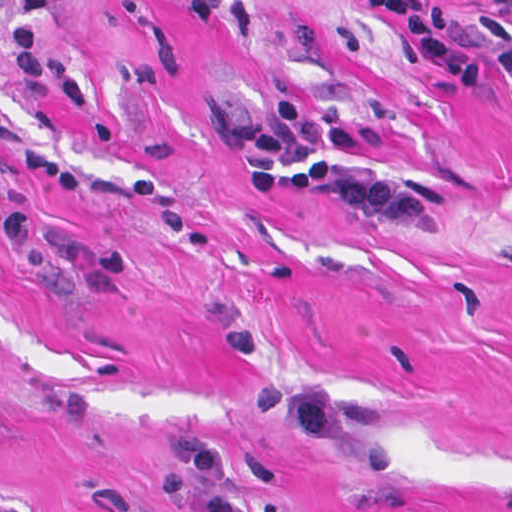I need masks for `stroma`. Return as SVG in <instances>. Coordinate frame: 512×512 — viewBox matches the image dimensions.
<instances>
[{"instance_id": "35a3bbf8", "label": "stroma", "mask_w": 512, "mask_h": 512, "mask_svg": "<svg viewBox=\"0 0 512 512\" xmlns=\"http://www.w3.org/2000/svg\"><path fill=\"white\" fill-rule=\"evenodd\" d=\"M0 0V512H512V75L465 87L367 0H58L9 70ZM478 17L484 0H410ZM288 95L391 223L250 185Z\"/></svg>"}]
</instances>
